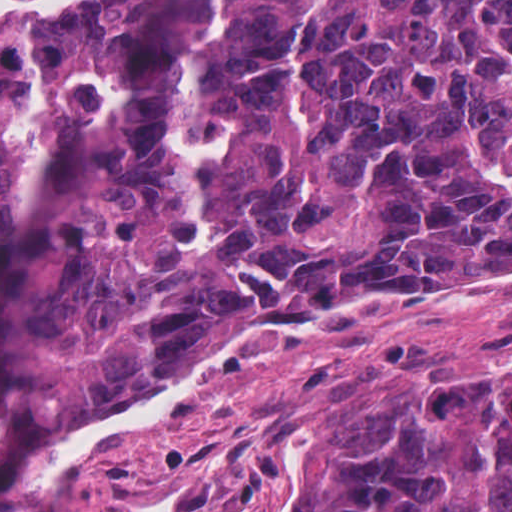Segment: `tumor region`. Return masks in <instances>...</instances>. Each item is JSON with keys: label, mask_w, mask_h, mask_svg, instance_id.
Segmentation results:
<instances>
[{"label": "tumor region", "mask_w": 512, "mask_h": 512, "mask_svg": "<svg viewBox=\"0 0 512 512\" xmlns=\"http://www.w3.org/2000/svg\"><path fill=\"white\" fill-rule=\"evenodd\" d=\"M123 6L0 51V278L43 133ZM218 17L210 254L187 258L195 168L165 134L186 56L41 307L43 403L143 391L260 333L191 397L223 392L333 302L512 268V0H218ZM276 474L307 512H512V371L323 418Z\"/></svg>", "instance_id": "obj_1"}]
</instances>
